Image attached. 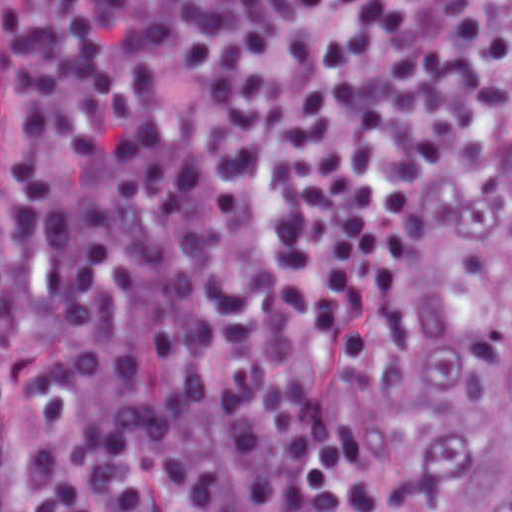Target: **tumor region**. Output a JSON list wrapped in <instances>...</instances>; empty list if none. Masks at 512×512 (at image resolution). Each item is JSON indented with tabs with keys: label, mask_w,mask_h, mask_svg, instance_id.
<instances>
[{
	"label": "tumor region",
	"mask_w": 512,
	"mask_h": 512,
	"mask_svg": "<svg viewBox=\"0 0 512 512\" xmlns=\"http://www.w3.org/2000/svg\"><path fill=\"white\" fill-rule=\"evenodd\" d=\"M408 396L458 509L512 512V135L446 244Z\"/></svg>",
	"instance_id": "tumor-region-1"
}]
</instances>
